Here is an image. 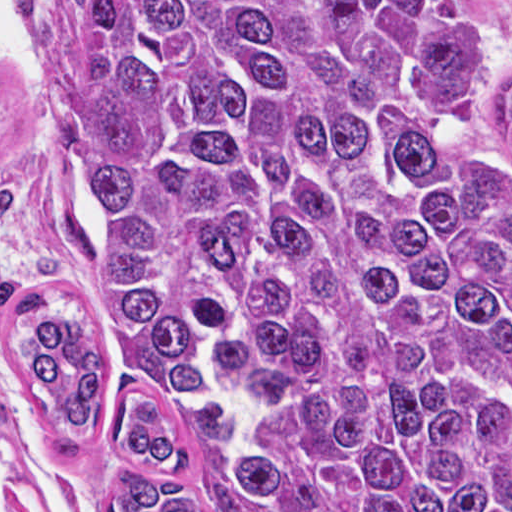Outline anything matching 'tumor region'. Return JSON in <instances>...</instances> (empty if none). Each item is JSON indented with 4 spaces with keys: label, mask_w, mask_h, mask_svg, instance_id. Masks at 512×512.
I'll use <instances>...</instances> for the list:
<instances>
[{
    "label": "tumor region",
    "mask_w": 512,
    "mask_h": 512,
    "mask_svg": "<svg viewBox=\"0 0 512 512\" xmlns=\"http://www.w3.org/2000/svg\"><path fill=\"white\" fill-rule=\"evenodd\" d=\"M93 214L38 222L90 306L16 400L109 436L115 512H210L163 395H224L247 512H512V162L459 0H23ZM512 144V93L504 109Z\"/></svg>",
    "instance_id": "e687c5a6"
}]
</instances>
